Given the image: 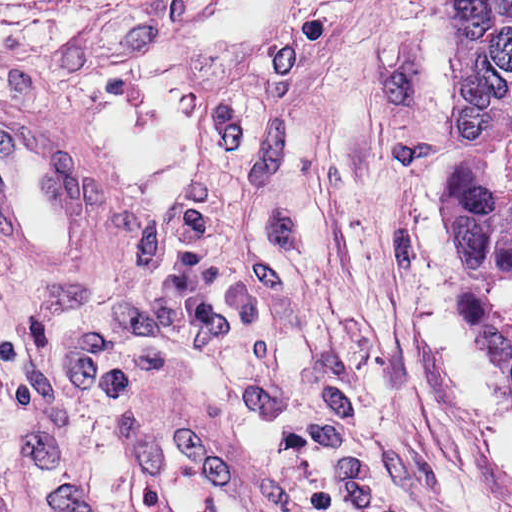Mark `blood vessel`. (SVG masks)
<instances>
[{
    "instance_id": "obj_1",
    "label": "blood vessel",
    "mask_w": 512,
    "mask_h": 512,
    "mask_svg": "<svg viewBox=\"0 0 512 512\" xmlns=\"http://www.w3.org/2000/svg\"><path fill=\"white\" fill-rule=\"evenodd\" d=\"M89 140L24 93L0 98V248L24 266L85 265ZM169 398L130 426V473L149 512H278L255 465Z\"/></svg>"
}]
</instances>
